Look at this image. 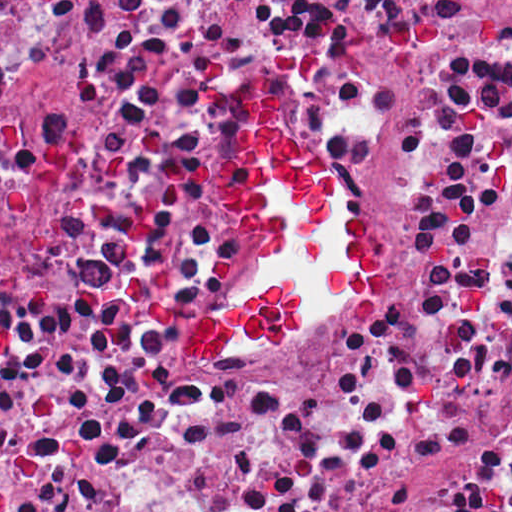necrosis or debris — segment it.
Instances as JSON below:
<instances>
[{"mask_svg":"<svg viewBox=\"0 0 512 512\" xmlns=\"http://www.w3.org/2000/svg\"><path fill=\"white\" fill-rule=\"evenodd\" d=\"M287 86L377 236V303L302 272L287 349L182 339L267 272L208 169ZM0 512H512V421L324 1L0 144Z\"/></svg>","mask_w":512,"mask_h":512,"instance_id":"4bbe7bcc","label":"necrosis or debris"}]
</instances>
